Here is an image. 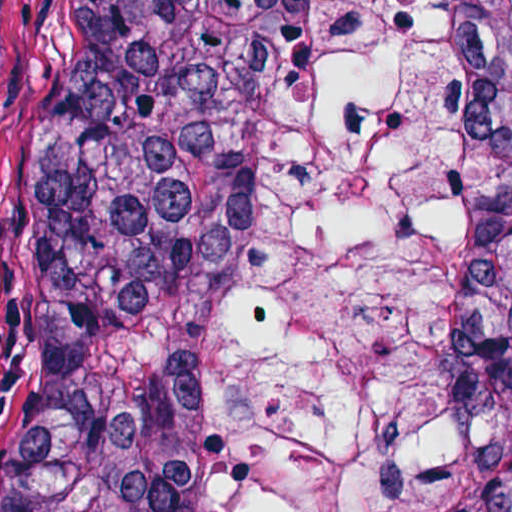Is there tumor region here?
Wrapping results in <instances>:
<instances>
[{
  "mask_svg": "<svg viewBox=\"0 0 512 512\" xmlns=\"http://www.w3.org/2000/svg\"><path fill=\"white\" fill-rule=\"evenodd\" d=\"M439 3L456 53L457 357L500 424L467 512H512V0ZM322 27L323 0H71L5 512H218L289 99Z\"/></svg>",
  "mask_w": 512,
  "mask_h": 512,
  "instance_id": "tumor-region-1",
  "label": "tumor region"
}]
</instances>
